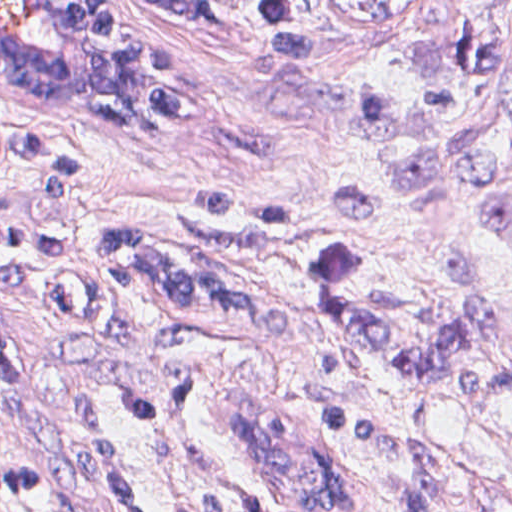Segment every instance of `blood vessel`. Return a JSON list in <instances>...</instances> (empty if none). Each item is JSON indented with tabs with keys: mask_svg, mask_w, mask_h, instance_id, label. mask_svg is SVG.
Instances as JSON below:
<instances>
[{
	"mask_svg": "<svg viewBox=\"0 0 512 512\" xmlns=\"http://www.w3.org/2000/svg\"><path fill=\"white\" fill-rule=\"evenodd\" d=\"M179 83V58L121 0H0V87L57 123L133 133Z\"/></svg>",
	"mask_w": 512,
	"mask_h": 512,
	"instance_id": "1",
	"label": "blood vessel"
}]
</instances>
